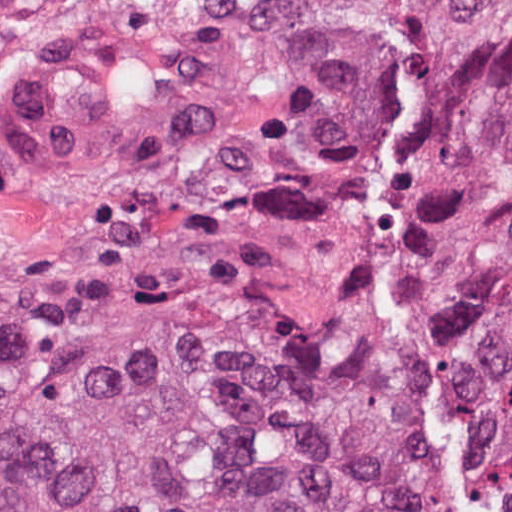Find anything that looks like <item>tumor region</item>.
Returning <instances> with one entry per match:
<instances>
[{
    "label": "tumor region",
    "instance_id": "1",
    "mask_svg": "<svg viewBox=\"0 0 512 512\" xmlns=\"http://www.w3.org/2000/svg\"><path fill=\"white\" fill-rule=\"evenodd\" d=\"M0 50L45 177L230 176L0 309V512H512V0H0Z\"/></svg>",
    "mask_w": 512,
    "mask_h": 512
}]
</instances>
